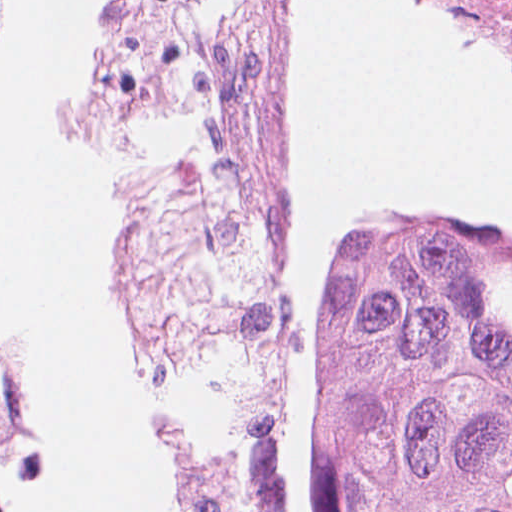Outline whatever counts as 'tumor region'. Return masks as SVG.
Instances as JSON below:
<instances>
[{
    "label": "tumor region",
    "mask_w": 512,
    "mask_h": 512,
    "mask_svg": "<svg viewBox=\"0 0 512 512\" xmlns=\"http://www.w3.org/2000/svg\"><path fill=\"white\" fill-rule=\"evenodd\" d=\"M39 447L37 380L0 346V512ZM319 477L337 512H512V231L404 222L349 248Z\"/></svg>",
    "instance_id": "obj_1"
}]
</instances>
